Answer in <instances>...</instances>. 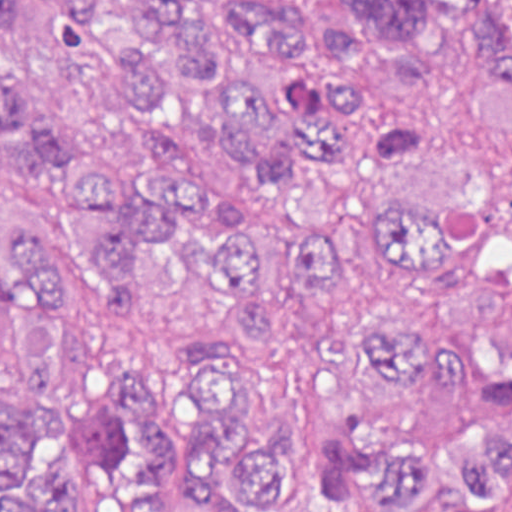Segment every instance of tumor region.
Returning <instances> with one entry per match:
<instances>
[{
	"label": "tumor region",
	"instance_id": "1",
	"mask_svg": "<svg viewBox=\"0 0 512 512\" xmlns=\"http://www.w3.org/2000/svg\"><path fill=\"white\" fill-rule=\"evenodd\" d=\"M402 115L298 227L178 149L194 108L264 198L365 75L299 0H0V512H512V0H334ZM74 282L71 287L64 272Z\"/></svg>",
	"mask_w": 512,
	"mask_h": 512
}]
</instances>
